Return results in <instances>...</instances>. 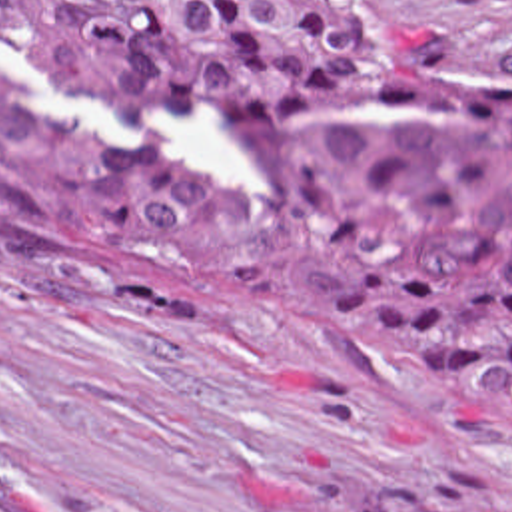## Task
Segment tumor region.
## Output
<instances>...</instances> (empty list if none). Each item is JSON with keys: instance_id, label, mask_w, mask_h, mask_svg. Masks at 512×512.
<instances>
[{"instance_id": "tumor-region-1", "label": "tumor region", "mask_w": 512, "mask_h": 512, "mask_svg": "<svg viewBox=\"0 0 512 512\" xmlns=\"http://www.w3.org/2000/svg\"><path fill=\"white\" fill-rule=\"evenodd\" d=\"M0 59L109 107L203 105L255 155L229 209L0 63V211L33 259L163 321L351 339L512 437V79H444L383 0H0Z\"/></svg>"}]
</instances>
